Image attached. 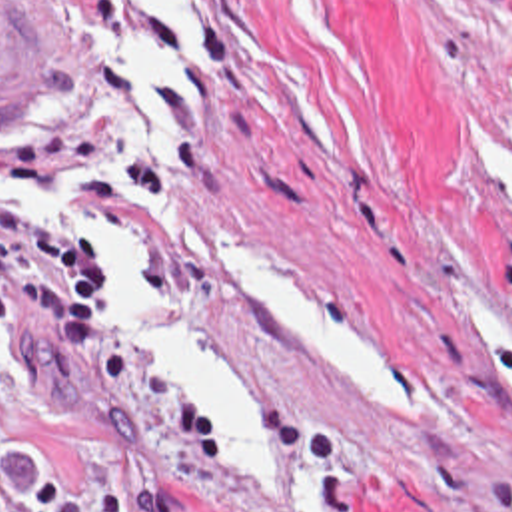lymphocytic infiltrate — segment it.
<instances>
[{"label":"lymphocytic infiltrate","mask_w":512,"mask_h":512,"mask_svg":"<svg viewBox=\"0 0 512 512\" xmlns=\"http://www.w3.org/2000/svg\"><path fill=\"white\" fill-rule=\"evenodd\" d=\"M25 309L49 323L69 355L101 345L99 260L35 220L0 208V335L19 333ZM0 512L89 511L57 479L37 481L33 497H9L0 461Z\"/></svg>","instance_id":"f902f5d3"}]
</instances>
